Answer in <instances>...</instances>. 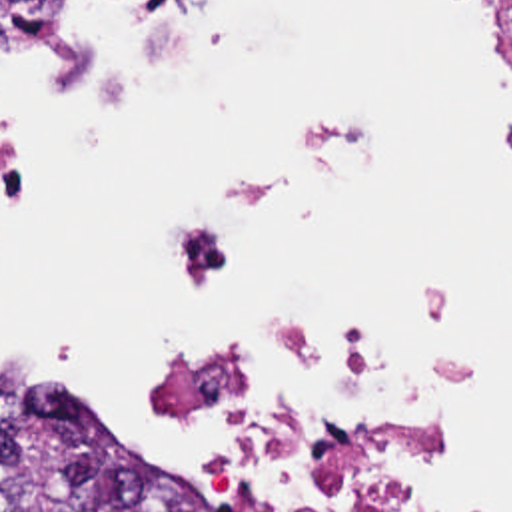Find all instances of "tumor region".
I'll list each match as a JSON object with an SVG mask.
<instances>
[{
  "label": "tumor region",
  "mask_w": 512,
  "mask_h": 512,
  "mask_svg": "<svg viewBox=\"0 0 512 512\" xmlns=\"http://www.w3.org/2000/svg\"><path fill=\"white\" fill-rule=\"evenodd\" d=\"M102 432L0 374V512H206Z\"/></svg>",
  "instance_id": "obj_1"
}]
</instances>
